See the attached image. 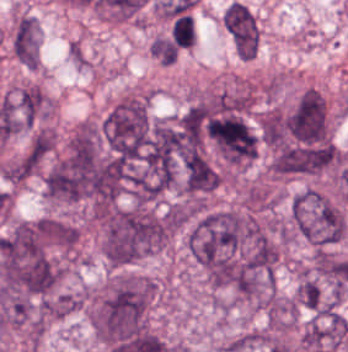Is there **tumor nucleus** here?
<instances>
[{
  "instance_id": "tumor-nucleus-8",
  "label": "tumor nucleus",
  "mask_w": 348,
  "mask_h": 352,
  "mask_svg": "<svg viewBox=\"0 0 348 352\" xmlns=\"http://www.w3.org/2000/svg\"><path fill=\"white\" fill-rule=\"evenodd\" d=\"M41 161L42 155L32 142L3 164V179L20 183L37 172Z\"/></svg>"
},
{
  "instance_id": "tumor-nucleus-9",
  "label": "tumor nucleus",
  "mask_w": 348,
  "mask_h": 352,
  "mask_svg": "<svg viewBox=\"0 0 348 352\" xmlns=\"http://www.w3.org/2000/svg\"><path fill=\"white\" fill-rule=\"evenodd\" d=\"M296 318V301L279 295L268 300L265 321L270 328L288 329Z\"/></svg>"
},
{
  "instance_id": "tumor-nucleus-5",
  "label": "tumor nucleus",
  "mask_w": 348,
  "mask_h": 352,
  "mask_svg": "<svg viewBox=\"0 0 348 352\" xmlns=\"http://www.w3.org/2000/svg\"><path fill=\"white\" fill-rule=\"evenodd\" d=\"M150 127L149 93L131 90L111 105L100 124L108 147H145Z\"/></svg>"
},
{
  "instance_id": "tumor-nucleus-10",
  "label": "tumor nucleus",
  "mask_w": 348,
  "mask_h": 352,
  "mask_svg": "<svg viewBox=\"0 0 348 352\" xmlns=\"http://www.w3.org/2000/svg\"><path fill=\"white\" fill-rule=\"evenodd\" d=\"M296 299L299 305L318 311L323 301V293L318 280L312 275L302 274L296 289Z\"/></svg>"
},
{
  "instance_id": "tumor-nucleus-6",
  "label": "tumor nucleus",
  "mask_w": 348,
  "mask_h": 352,
  "mask_svg": "<svg viewBox=\"0 0 348 352\" xmlns=\"http://www.w3.org/2000/svg\"><path fill=\"white\" fill-rule=\"evenodd\" d=\"M348 335V320L338 310L318 312L306 325L301 343L307 352L337 349Z\"/></svg>"
},
{
  "instance_id": "tumor-nucleus-11",
  "label": "tumor nucleus",
  "mask_w": 348,
  "mask_h": 352,
  "mask_svg": "<svg viewBox=\"0 0 348 352\" xmlns=\"http://www.w3.org/2000/svg\"><path fill=\"white\" fill-rule=\"evenodd\" d=\"M55 140L53 131L47 127H40L34 131L29 147L44 157L52 151Z\"/></svg>"
},
{
  "instance_id": "tumor-nucleus-4",
  "label": "tumor nucleus",
  "mask_w": 348,
  "mask_h": 352,
  "mask_svg": "<svg viewBox=\"0 0 348 352\" xmlns=\"http://www.w3.org/2000/svg\"><path fill=\"white\" fill-rule=\"evenodd\" d=\"M287 233L316 246H325L344 233L341 211L314 189L299 193L290 201Z\"/></svg>"
},
{
  "instance_id": "tumor-nucleus-2",
  "label": "tumor nucleus",
  "mask_w": 348,
  "mask_h": 352,
  "mask_svg": "<svg viewBox=\"0 0 348 352\" xmlns=\"http://www.w3.org/2000/svg\"><path fill=\"white\" fill-rule=\"evenodd\" d=\"M154 293L150 277L117 273L90 299L87 319L93 332L108 343L143 332Z\"/></svg>"
},
{
  "instance_id": "tumor-nucleus-1",
  "label": "tumor nucleus",
  "mask_w": 348,
  "mask_h": 352,
  "mask_svg": "<svg viewBox=\"0 0 348 352\" xmlns=\"http://www.w3.org/2000/svg\"><path fill=\"white\" fill-rule=\"evenodd\" d=\"M42 184L51 199L102 201L109 194V172L96 132L73 133L47 167Z\"/></svg>"
},
{
  "instance_id": "tumor-nucleus-3",
  "label": "tumor nucleus",
  "mask_w": 348,
  "mask_h": 352,
  "mask_svg": "<svg viewBox=\"0 0 348 352\" xmlns=\"http://www.w3.org/2000/svg\"><path fill=\"white\" fill-rule=\"evenodd\" d=\"M99 250L110 265L137 262L162 248L170 214L147 205L112 206L96 220Z\"/></svg>"
},
{
  "instance_id": "tumor-nucleus-7",
  "label": "tumor nucleus",
  "mask_w": 348,
  "mask_h": 352,
  "mask_svg": "<svg viewBox=\"0 0 348 352\" xmlns=\"http://www.w3.org/2000/svg\"><path fill=\"white\" fill-rule=\"evenodd\" d=\"M222 22L236 52L246 61L255 57L259 46V29L253 12L234 0L225 9Z\"/></svg>"
}]
</instances>
